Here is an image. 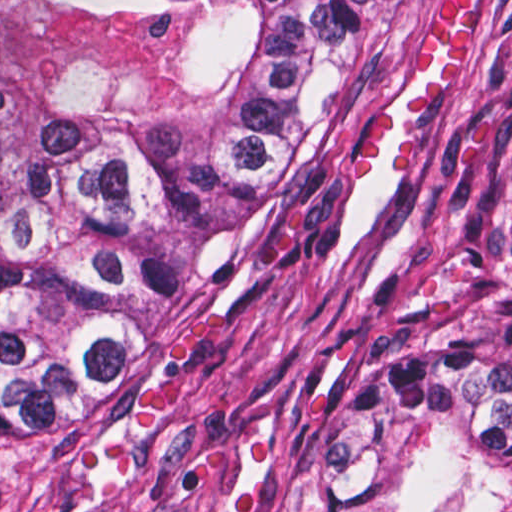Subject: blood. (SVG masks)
<instances>
[{
    "instance_id": "obj_1",
    "label": "blood",
    "mask_w": 512,
    "mask_h": 512,
    "mask_svg": "<svg viewBox=\"0 0 512 512\" xmlns=\"http://www.w3.org/2000/svg\"><path fill=\"white\" fill-rule=\"evenodd\" d=\"M475 34V0H441L422 35L383 76L360 116L354 134L353 177L364 182L389 134L391 119L404 92L423 75H447L471 55Z\"/></svg>"
}]
</instances>
